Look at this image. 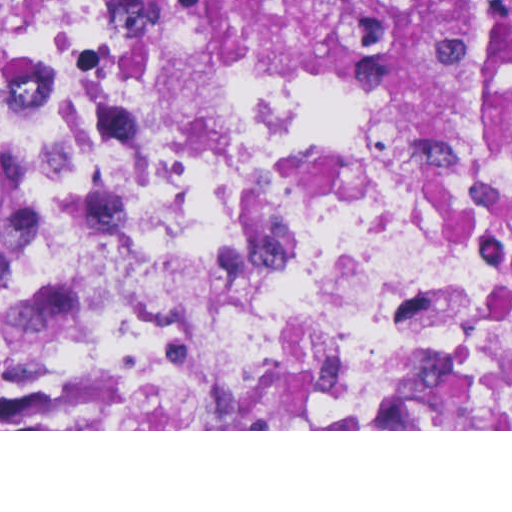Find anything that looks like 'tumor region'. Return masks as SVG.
Here are the masks:
<instances>
[{"label": "tumor region", "instance_id": "obj_1", "mask_svg": "<svg viewBox=\"0 0 512 512\" xmlns=\"http://www.w3.org/2000/svg\"><path fill=\"white\" fill-rule=\"evenodd\" d=\"M166 1L201 39L305 75L402 133L512 160V0Z\"/></svg>", "mask_w": 512, "mask_h": 512}]
</instances>
